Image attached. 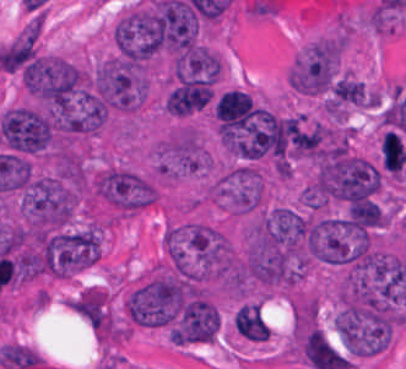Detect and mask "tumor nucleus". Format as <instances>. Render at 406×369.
I'll use <instances>...</instances> for the list:
<instances>
[{
    "label": "tumor nucleus",
    "mask_w": 406,
    "mask_h": 369,
    "mask_svg": "<svg viewBox=\"0 0 406 369\" xmlns=\"http://www.w3.org/2000/svg\"><path fill=\"white\" fill-rule=\"evenodd\" d=\"M231 323L236 335L244 341L263 343L271 333L259 302H246L241 305Z\"/></svg>",
    "instance_id": "6"
},
{
    "label": "tumor nucleus",
    "mask_w": 406,
    "mask_h": 369,
    "mask_svg": "<svg viewBox=\"0 0 406 369\" xmlns=\"http://www.w3.org/2000/svg\"><path fill=\"white\" fill-rule=\"evenodd\" d=\"M292 350L311 369H345V357L318 326L296 325Z\"/></svg>",
    "instance_id": "5"
},
{
    "label": "tumor nucleus",
    "mask_w": 406,
    "mask_h": 369,
    "mask_svg": "<svg viewBox=\"0 0 406 369\" xmlns=\"http://www.w3.org/2000/svg\"><path fill=\"white\" fill-rule=\"evenodd\" d=\"M109 39L117 59L143 67L159 49L161 13L152 4H133L112 22Z\"/></svg>",
    "instance_id": "2"
},
{
    "label": "tumor nucleus",
    "mask_w": 406,
    "mask_h": 369,
    "mask_svg": "<svg viewBox=\"0 0 406 369\" xmlns=\"http://www.w3.org/2000/svg\"><path fill=\"white\" fill-rule=\"evenodd\" d=\"M340 52L337 37H318L291 61L286 81L300 95L314 96L328 89Z\"/></svg>",
    "instance_id": "4"
},
{
    "label": "tumor nucleus",
    "mask_w": 406,
    "mask_h": 369,
    "mask_svg": "<svg viewBox=\"0 0 406 369\" xmlns=\"http://www.w3.org/2000/svg\"><path fill=\"white\" fill-rule=\"evenodd\" d=\"M18 80L36 107L55 116H75L86 107L87 78L69 58L36 51Z\"/></svg>",
    "instance_id": "1"
},
{
    "label": "tumor nucleus",
    "mask_w": 406,
    "mask_h": 369,
    "mask_svg": "<svg viewBox=\"0 0 406 369\" xmlns=\"http://www.w3.org/2000/svg\"><path fill=\"white\" fill-rule=\"evenodd\" d=\"M261 170L251 162H238L218 172L209 184V198L233 216L253 213L265 202Z\"/></svg>",
    "instance_id": "3"
}]
</instances>
